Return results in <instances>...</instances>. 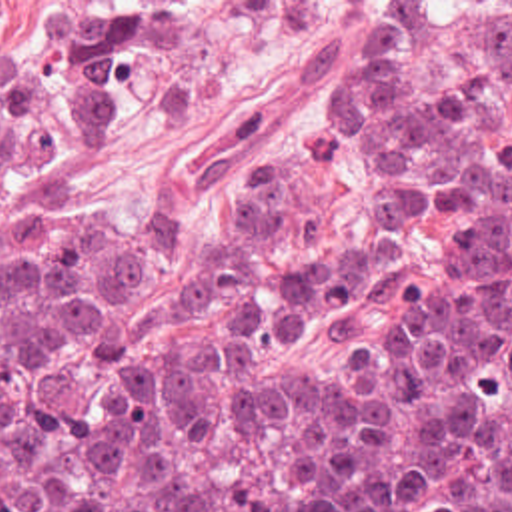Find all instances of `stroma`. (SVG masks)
Here are the masks:
<instances>
[{"mask_svg":"<svg viewBox=\"0 0 512 512\" xmlns=\"http://www.w3.org/2000/svg\"><path fill=\"white\" fill-rule=\"evenodd\" d=\"M74 0H0V50L17 48ZM338 0H170L174 20L158 36L144 74L138 128L150 140H226L246 130L270 96L288 84L316 50ZM336 46L320 70L256 140L202 170L174 174L170 158L132 128L60 160L68 188L52 220L62 232L90 216L120 226L182 222L214 232V214L242 164L266 146L292 154L298 192L332 210L338 238L374 242L378 266L352 298L302 322L294 334L318 370L344 352L332 334L338 314L362 316L394 282H410L428 264V234L416 222L380 214L372 174L360 152L326 156L316 126L330 108Z\"/></svg>","mask_w":512,"mask_h":512,"instance_id":"35a3bbf8","label":"stroma"}]
</instances>
